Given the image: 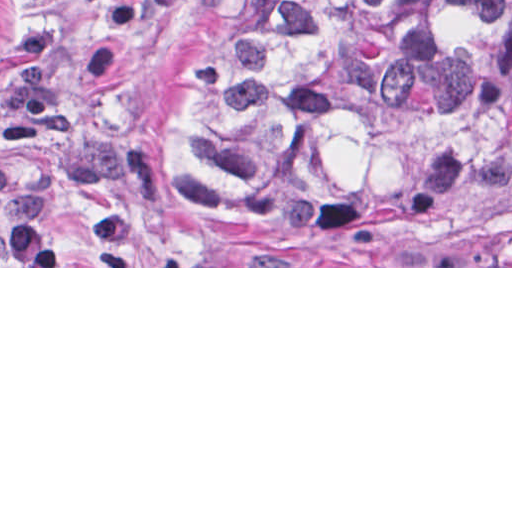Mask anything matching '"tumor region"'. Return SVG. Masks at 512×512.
I'll list each match as a JSON object with an SVG mask.
<instances>
[{
	"label": "tumor region",
	"mask_w": 512,
	"mask_h": 512,
	"mask_svg": "<svg viewBox=\"0 0 512 512\" xmlns=\"http://www.w3.org/2000/svg\"><path fill=\"white\" fill-rule=\"evenodd\" d=\"M511 146L512 0H232L187 182L284 266H445L431 224Z\"/></svg>",
	"instance_id": "tumor-region-1"
}]
</instances>
